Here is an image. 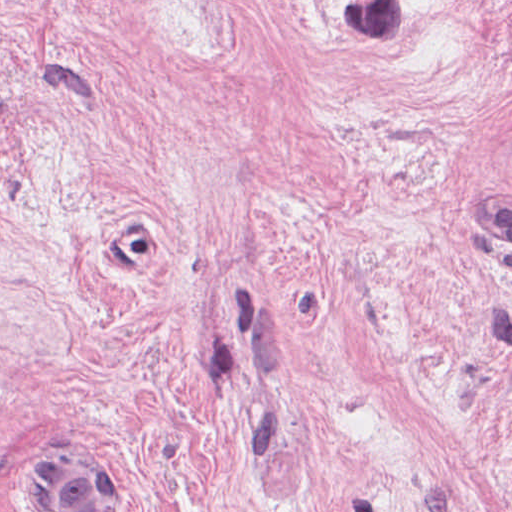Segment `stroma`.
<instances>
[{"label":"stroma","mask_w":512,"mask_h":512,"mask_svg":"<svg viewBox=\"0 0 512 512\" xmlns=\"http://www.w3.org/2000/svg\"><path fill=\"white\" fill-rule=\"evenodd\" d=\"M57 449L512 512V0H0V512Z\"/></svg>","instance_id":"stroma-1"}]
</instances>
